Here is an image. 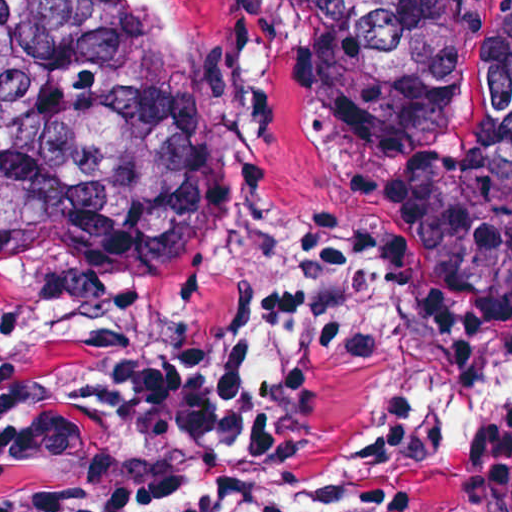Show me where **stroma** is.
<instances>
[{"label": "stroma", "instance_id": "obj_1", "mask_svg": "<svg viewBox=\"0 0 512 512\" xmlns=\"http://www.w3.org/2000/svg\"><path fill=\"white\" fill-rule=\"evenodd\" d=\"M237 0H168L185 40L140 5V41L214 84L144 117L172 170L223 203L291 276L322 250L329 213L368 207L391 232L387 342L322 367L300 390L373 443L415 448L420 480L396 512H512V400L465 458L441 459L434 417L411 413L424 385L466 392L512 372V325L467 303L404 253L385 184L450 154L482 105L501 0H458V91L422 136L379 156L361 99L319 67L302 25L237 19ZM243 340L111 317H25L0 333V382L57 379L94 356L178 351L212 371L242 363Z\"/></svg>", "mask_w": 512, "mask_h": 512}]
</instances>
